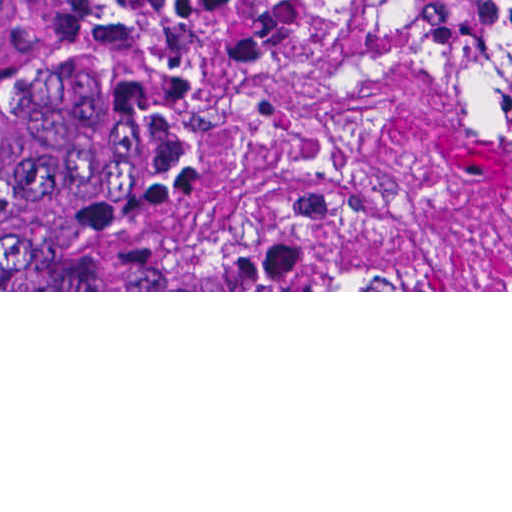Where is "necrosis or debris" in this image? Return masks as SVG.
Returning <instances> with one entry per match:
<instances>
[{"mask_svg":"<svg viewBox=\"0 0 512 512\" xmlns=\"http://www.w3.org/2000/svg\"><path fill=\"white\" fill-rule=\"evenodd\" d=\"M145 275L151 290H447L439 255L316 158L228 164Z\"/></svg>","mask_w":512,"mask_h":512,"instance_id":"necrosis-or-debris-1","label":"necrosis or debris"}]
</instances>
